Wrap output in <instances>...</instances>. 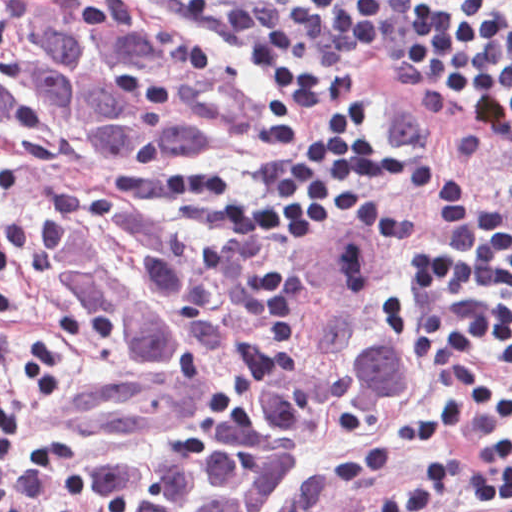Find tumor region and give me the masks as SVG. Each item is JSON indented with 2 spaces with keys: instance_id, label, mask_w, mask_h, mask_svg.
<instances>
[{
  "instance_id": "1",
  "label": "tumor region",
  "mask_w": 512,
  "mask_h": 512,
  "mask_svg": "<svg viewBox=\"0 0 512 512\" xmlns=\"http://www.w3.org/2000/svg\"><path fill=\"white\" fill-rule=\"evenodd\" d=\"M245 88L89 0H0V142L235 150ZM381 230L182 240L109 196L43 220L36 273L121 373L58 396L0 351V512H274L425 373Z\"/></svg>"
}]
</instances>
